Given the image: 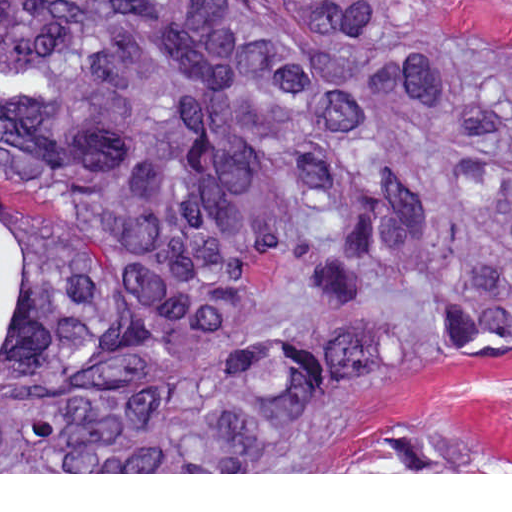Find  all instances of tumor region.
I'll return each mask as SVG.
<instances>
[{
  "mask_svg": "<svg viewBox=\"0 0 512 512\" xmlns=\"http://www.w3.org/2000/svg\"><path fill=\"white\" fill-rule=\"evenodd\" d=\"M0 227V472L492 471L327 441L512 362L509 46L416 0H0Z\"/></svg>",
  "mask_w": 512,
  "mask_h": 512,
  "instance_id": "e687c5a6",
  "label": "tumor region"
}]
</instances>
